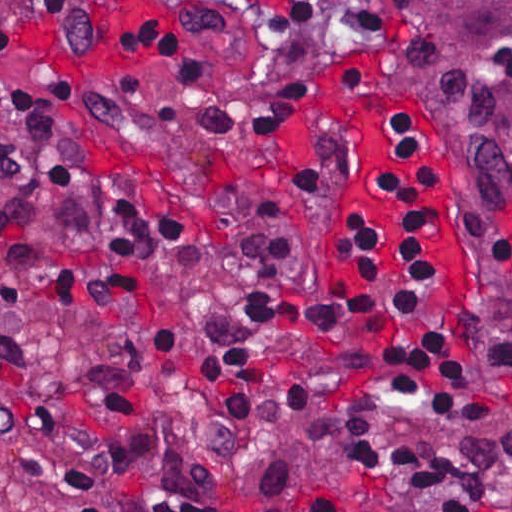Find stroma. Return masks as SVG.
Returning a JSON list of instances; mask_svg holds the SVG:
<instances>
[{
    "mask_svg": "<svg viewBox=\"0 0 512 512\" xmlns=\"http://www.w3.org/2000/svg\"><path fill=\"white\" fill-rule=\"evenodd\" d=\"M93 52L69 53L36 26L16 27L12 48L0 49V82L53 90L62 79L78 88V110L60 117V136L106 173L135 174L167 188L181 204L192 235L208 248L226 246L230 208L249 191L300 222L306 272L290 287L298 304H317L355 291L341 231L352 212L370 214L383 256L400 270L403 241L393 209L371 186V173L390 142L405 170L436 210L469 236L466 208L447 178L386 113L383 81L359 0H333L343 48L324 62L308 95V117L337 131L343 175L332 194L293 192L287 169L298 133L250 139L199 131L187 116L186 91L168 73L128 51V31L166 27L202 44L219 72L233 81H261L281 61L280 44L238 43L216 33L173 0H102ZM43 294L0 266V340L23 337L41 362L46 394L64 421L94 415L105 373L120 359V342L99 320L77 310L42 309ZM62 490L59 466L25 441H0V512H51Z\"/></svg>",
    "mask_w": 512,
    "mask_h": 512,
    "instance_id": "stroma-1",
    "label": "stroma"
}]
</instances>
